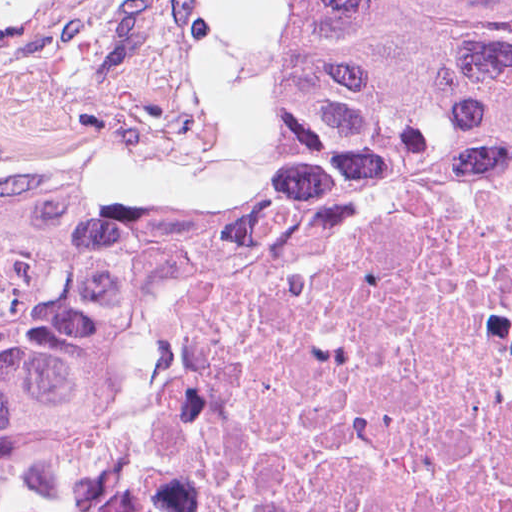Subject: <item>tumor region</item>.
Returning a JSON list of instances; mask_svg holds the SVG:
<instances>
[{
    "instance_id": "obj_1",
    "label": "tumor region",
    "mask_w": 512,
    "mask_h": 512,
    "mask_svg": "<svg viewBox=\"0 0 512 512\" xmlns=\"http://www.w3.org/2000/svg\"><path fill=\"white\" fill-rule=\"evenodd\" d=\"M511 129L512 0H297L268 153L0 252V512H142L189 348Z\"/></svg>"
}]
</instances>
